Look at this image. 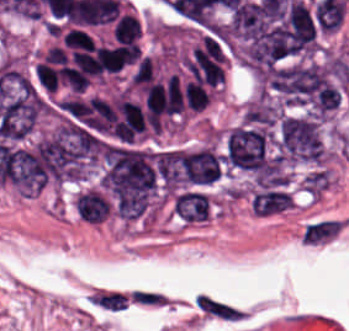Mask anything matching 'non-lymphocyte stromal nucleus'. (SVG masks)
<instances>
[{"label":"non-lymphocyte stromal nucleus","instance_id":"1","mask_svg":"<svg viewBox=\"0 0 349 331\" xmlns=\"http://www.w3.org/2000/svg\"><path fill=\"white\" fill-rule=\"evenodd\" d=\"M346 222L340 217H320L307 221L299 230L301 242L311 247H321L333 242L345 229Z\"/></svg>","mask_w":349,"mask_h":331},{"label":"non-lymphocyte stromal nucleus","instance_id":"2","mask_svg":"<svg viewBox=\"0 0 349 331\" xmlns=\"http://www.w3.org/2000/svg\"><path fill=\"white\" fill-rule=\"evenodd\" d=\"M195 303L203 317L221 320H241L240 310L205 295L199 294Z\"/></svg>","mask_w":349,"mask_h":331}]
</instances>
